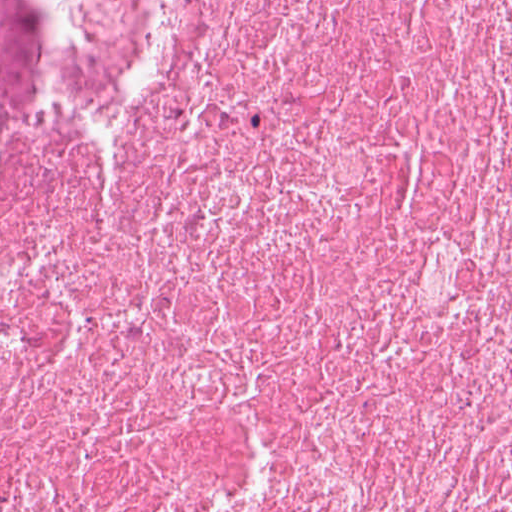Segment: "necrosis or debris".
Segmentation results:
<instances>
[{
    "label": "necrosis or debris",
    "instance_id": "4bbe7bcc",
    "mask_svg": "<svg viewBox=\"0 0 512 512\" xmlns=\"http://www.w3.org/2000/svg\"><path fill=\"white\" fill-rule=\"evenodd\" d=\"M0 512H512V0H0Z\"/></svg>",
    "mask_w": 512,
    "mask_h": 512
}]
</instances>
